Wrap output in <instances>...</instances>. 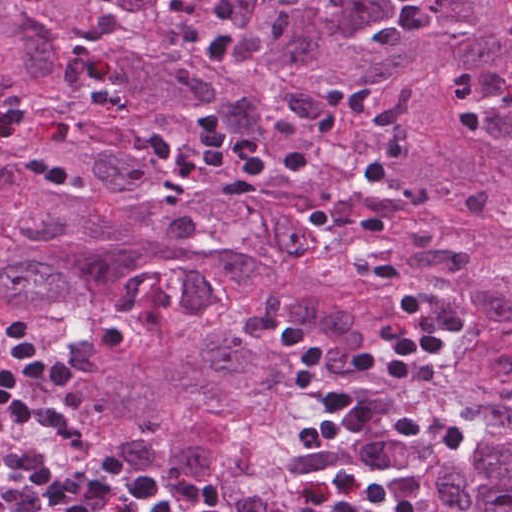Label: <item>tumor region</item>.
I'll use <instances>...</instances> for the list:
<instances>
[{"label": "tumor region", "instance_id": "obj_1", "mask_svg": "<svg viewBox=\"0 0 512 512\" xmlns=\"http://www.w3.org/2000/svg\"><path fill=\"white\" fill-rule=\"evenodd\" d=\"M512 0H0V128L426 512H512ZM218 114L253 153L307 156L248 199L177 148ZM456 329L408 386L366 375L403 333L359 231ZM283 320L330 385L465 433L459 451L343 431L295 388Z\"/></svg>", "mask_w": 512, "mask_h": 512}]
</instances>
